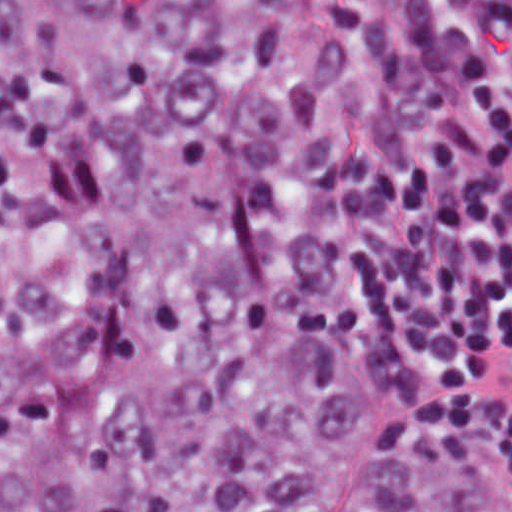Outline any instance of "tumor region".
Listing matches in <instances>:
<instances>
[{
	"label": "tumor region",
	"mask_w": 512,
	"mask_h": 512,
	"mask_svg": "<svg viewBox=\"0 0 512 512\" xmlns=\"http://www.w3.org/2000/svg\"><path fill=\"white\" fill-rule=\"evenodd\" d=\"M373 0H0V512H512L324 267Z\"/></svg>",
	"instance_id": "e687c5a6"
}]
</instances>
